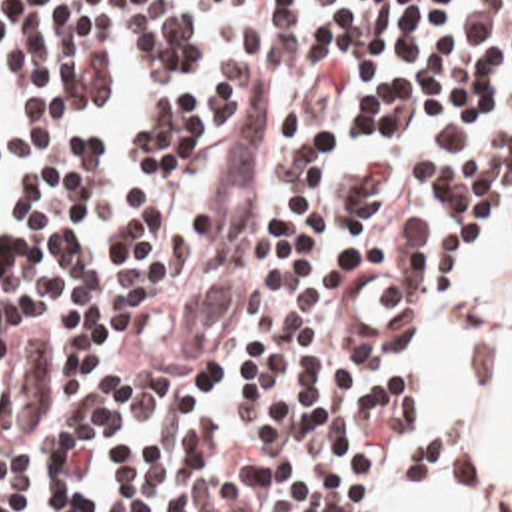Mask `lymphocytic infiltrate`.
<instances>
[{
    "instance_id": "lymphocytic-infiltrate-1",
    "label": "lymphocytic infiltrate",
    "mask_w": 512,
    "mask_h": 512,
    "mask_svg": "<svg viewBox=\"0 0 512 512\" xmlns=\"http://www.w3.org/2000/svg\"><path fill=\"white\" fill-rule=\"evenodd\" d=\"M237 78L149 86L145 186L77 140L27 184L0 250V512H380L418 408L408 338H362L342 272L418 288V322L512 210V0H223ZM197 50L191 0H0L31 122L103 98L111 38ZM265 76L259 224L197 354L171 328L215 220L233 112ZM418 326V324H416Z\"/></svg>"
}]
</instances>
